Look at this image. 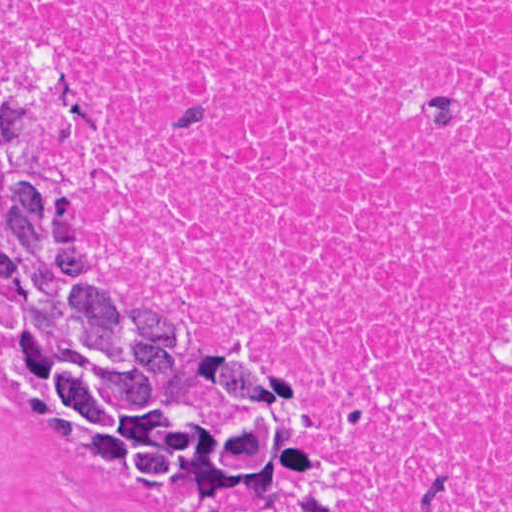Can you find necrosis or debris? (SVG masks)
Listing matches in <instances>:
<instances>
[{
	"instance_id": "1",
	"label": "necrosis or debris",
	"mask_w": 512,
	"mask_h": 512,
	"mask_svg": "<svg viewBox=\"0 0 512 512\" xmlns=\"http://www.w3.org/2000/svg\"><path fill=\"white\" fill-rule=\"evenodd\" d=\"M89 13L109 260L337 375L365 512H512V1Z\"/></svg>"
}]
</instances>
